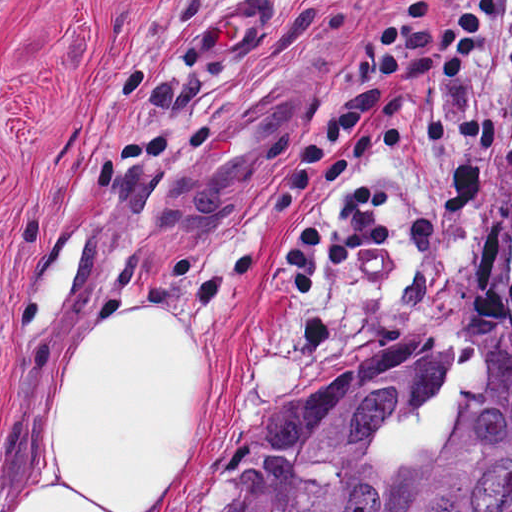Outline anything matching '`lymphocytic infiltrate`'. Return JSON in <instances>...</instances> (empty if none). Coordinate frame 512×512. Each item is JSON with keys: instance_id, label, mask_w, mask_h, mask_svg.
<instances>
[{"instance_id": "lymphocytic-infiltrate-1", "label": "lymphocytic infiltrate", "mask_w": 512, "mask_h": 512, "mask_svg": "<svg viewBox=\"0 0 512 512\" xmlns=\"http://www.w3.org/2000/svg\"><path fill=\"white\" fill-rule=\"evenodd\" d=\"M512 79V0H454L435 16L421 0L375 29L348 74L340 113L290 167L275 223L360 171V184L311 221L275 260L291 298L310 297L327 272L381 249L395 202L378 158L426 153L436 138L467 136L512 164V126L483 87Z\"/></svg>"}]
</instances>
